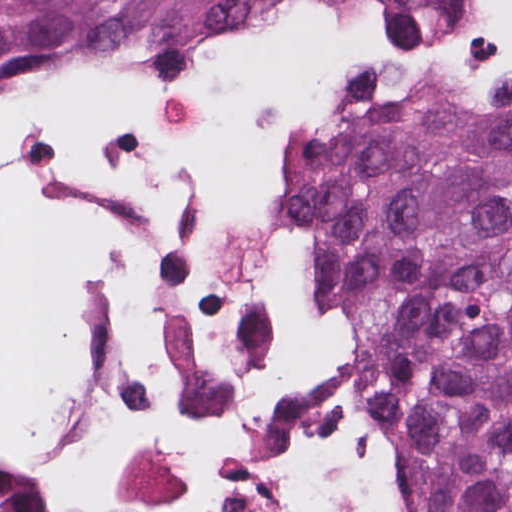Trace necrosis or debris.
I'll list each match as a JSON object with an SVG mask.
<instances>
[{
	"label": "necrosis or debris",
	"mask_w": 512,
	"mask_h": 512,
	"mask_svg": "<svg viewBox=\"0 0 512 512\" xmlns=\"http://www.w3.org/2000/svg\"><path fill=\"white\" fill-rule=\"evenodd\" d=\"M0 512H418L284 118L159 54H0Z\"/></svg>",
	"instance_id": "necrosis-or-debris-1"
}]
</instances>
